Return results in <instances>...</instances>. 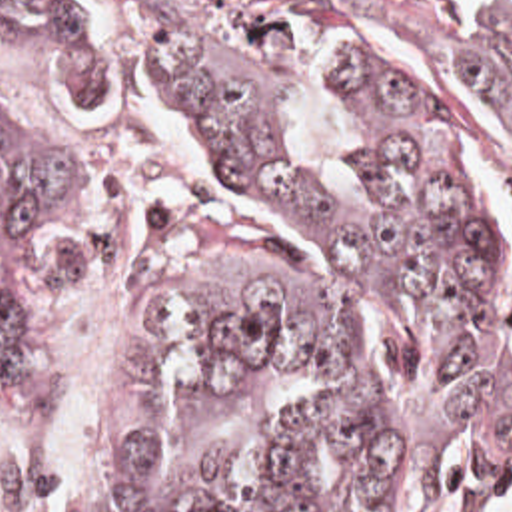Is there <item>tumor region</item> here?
<instances>
[{
    "label": "tumor region",
    "mask_w": 512,
    "mask_h": 512,
    "mask_svg": "<svg viewBox=\"0 0 512 512\" xmlns=\"http://www.w3.org/2000/svg\"><path fill=\"white\" fill-rule=\"evenodd\" d=\"M133 35L217 169L301 249L223 205L159 217L133 313L149 349L121 395L115 512H413L453 443L477 437L512 477V253L471 163V105L512 103V23H401L433 97L337 47L329 69L367 143L341 205L293 181L289 45L321 19L243 0H85ZM0 47H61L75 99L105 105L113 55L81 0H0ZM75 153L0 107V219L67 225L55 281L93 265L115 209ZM41 317L0 293V385L23 377ZM0 512H41L33 475L2 467Z\"/></svg>",
    "instance_id": "obj_1"
}]
</instances>
